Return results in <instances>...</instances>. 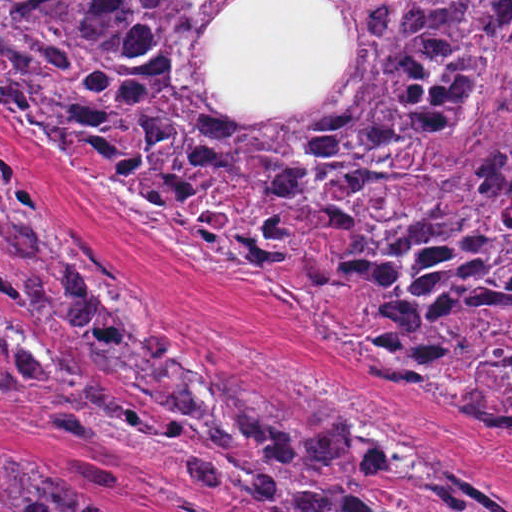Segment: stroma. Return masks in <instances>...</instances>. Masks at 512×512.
I'll list each match as a JSON object with an SVG mask.
<instances>
[{
    "label": "stroma",
    "instance_id": "obj_1",
    "mask_svg": "<svg viewBox=\"0 0 512 512\" xmlns=\"http://www.w3.org/2000/svg\"><path fill=\"white\" fill-rule=\"evenodd\" d=\"M0 1H233L201 43L214 95L227 109H288L322 92L351 52V32L328 1L512 0ZM0 200L91 232L125 273L127 303L153 337L285 412L296 428L314 424L321 408L331 410L403 462L431 467L454 458L512 501V435L456 410L425 366L421 383L375 375L282 290L244 271L204 264L82 180L1 101ZM27 265L0 248L1 270L17 275ZM0 326L49 360L66 355L100 370L123 403L177 419L156 395L121 389L84 351L33 336L1 297ZM425 337L512 344V329L454 323ZM185 444L182 430L132 457L121 432L67 395L40 397L25 412L0 401L2 454L40 455L83 503L106 512H254L211 497Z\"/></svg>",
    "mask_w": 512,
    "mask_h": 512
}]
</instances>
